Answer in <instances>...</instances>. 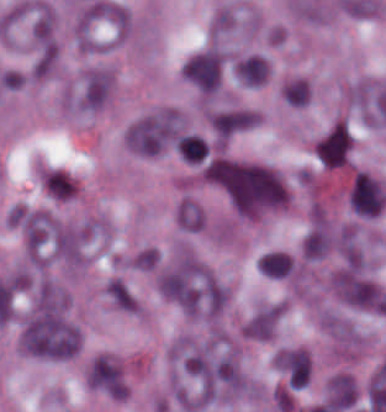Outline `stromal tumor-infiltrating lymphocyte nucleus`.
<instances>
[{"mask_svg": "<svg viewBox=\"0 0 386 412\" xmlns=\"http://www.w3.org/2000/svg\"><path fill=\"white\" fill-rule=\"evenodd\" d=\"M258 269L265 277L283 278L291 273L292 258L280 251L266 253L257 261Z\"/></svg>", "mask_w": 386, "mask_h": 412, "instance_id": "stromal-tumor-infiltrating-lymphocyte-nucleus-1", "label": "stromal tumor-infiltrating lymphocyte nucleus"}]
</instances>
